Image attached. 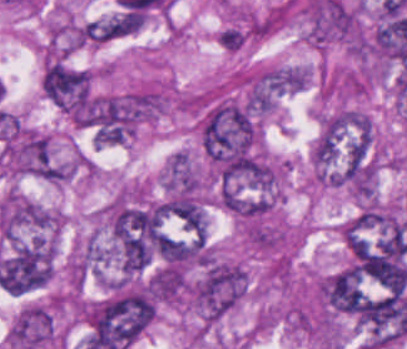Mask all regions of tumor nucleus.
I'll list each match as a JSON object with an SVG mask.
<instances>
[{"label":"tumor nucleus","mask_w":407,"mask_h":349,"mask_svg":"<svg viewBox=\"0 0 407 349\" xmlns=\"http://www.w3.org/2000/svg\"><path fill=\"white\" fill-rule=\"evenodd\" d=\"M93 71L57 62L47 63L42 78L45 98L73 124L87 120Z\"/></svg>","instance_id":"obj_1"}]
</instances>
